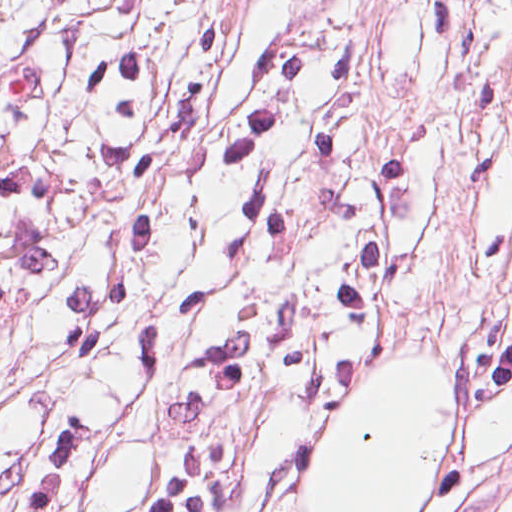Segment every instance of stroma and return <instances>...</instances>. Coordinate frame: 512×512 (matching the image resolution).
<instances>
[{
  "label": "stroma",
  "mask_w": 512,
  "mask_h": 512,
  "mask_svg": "<svg viewBox=\"0 0 512 512\" xmlns=\"http://www.w3.org/2000/svg\"><path fill=\"white\" fill-rule=\"evenodd\" d=\"M390 0H0V512H282Z\"/></svg>",
  "instance_id": "stroma-1"
}]
</instances>
